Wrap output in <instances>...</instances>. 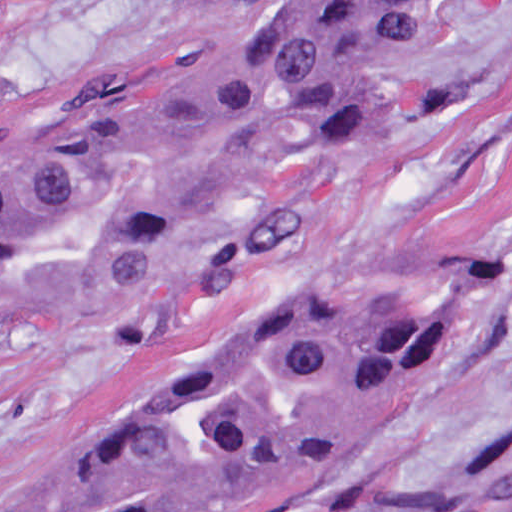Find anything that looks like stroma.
<instances>
[{"instance_id":"35a3bbf8","label":"stroma","mask_w":512,"mask_h":512,"mask_svg":"<svg viewBox=\"0 0 512 512\" xmlns=\"http://www.w3.org/2000/svg\"><path fill=\"white\" fill-rule=\"evenodd\" d=\"M223 0H0V114L136 49L191 45L242 91L253 154L216 252L296 303L397 298L432 350L395 402L232 512H388L479 459L512 406L482 354L512 317V0H437L384 64L383 149L308 132L264 69L268 21ZM227 308L222 260L56 288L0 324V509L28 464L110 406L144 361Z\"/></svg>"}]
</instances>
